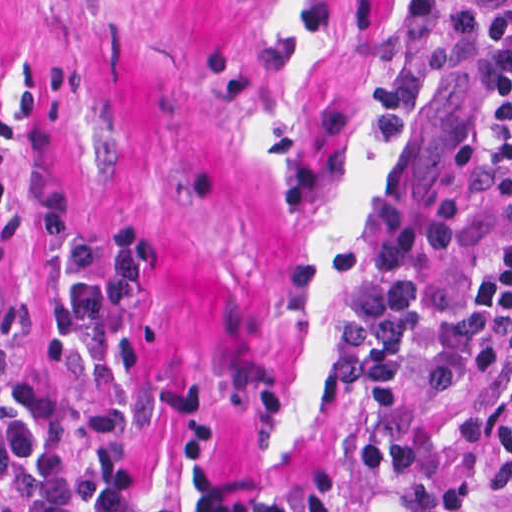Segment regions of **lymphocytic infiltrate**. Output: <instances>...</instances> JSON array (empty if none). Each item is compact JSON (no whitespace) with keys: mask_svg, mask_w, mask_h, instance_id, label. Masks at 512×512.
Returning a JSON list of instances; mask_svg holds the SVG:
<instances>
[{"mask_svg":"<svg viewBox=\"0 0 512 512\" xmlns=\"http://www.w3.org/2000/svg\"><path fill=\"white\" fill-rule=\"evenodd\" d=\"M440 1L447 36L476 77L482 118L498 142L505 211L465 288L413 334L423 386L465 382L512 343V0ZM38 227L58 261L40 319L45 351L66 363L74 345L91 344L114 391L167 428L187 487L169 497L145 492L136 426L105 406L87 420L79 454H70V432L47 387L21 381L0 388V512H346L321 490L278 495L237 482L229 433L208 386L132 385L118 377V344L158 256L148 231L133 224L101 230L63 210Z\"/></svg>","mask_w":512,"mask_h":512,"instance_id":"1","label":"lymphocytic infiltrate"}]
</instances>
